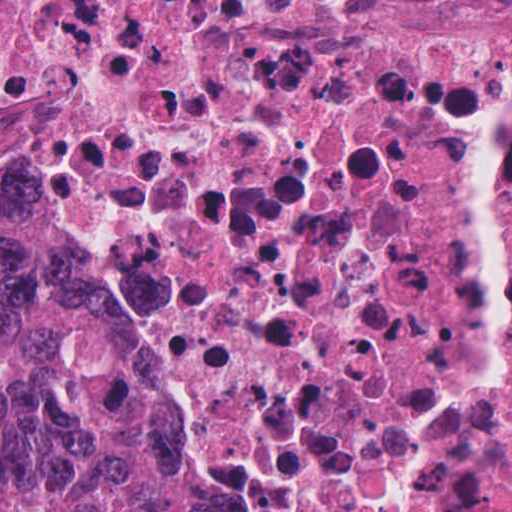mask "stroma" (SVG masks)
Listing matches in <instances>:
<instances>
[{
  "mask_svg": "<svg viewBox=\"0 0 512 512\" xmlns=\"http://www.w3.org/2000/svg\"><path fill=\"white\" fill-rule=\"evenodd\" d=\"M408 20L449 32H495L512 28V7L475 0H405Z\"/></svg>",
  "mask_w": 512,
  "mask_h": 512,
  "instance_id": "obj_1",
  "label": "stroma"
}]
</instances>
